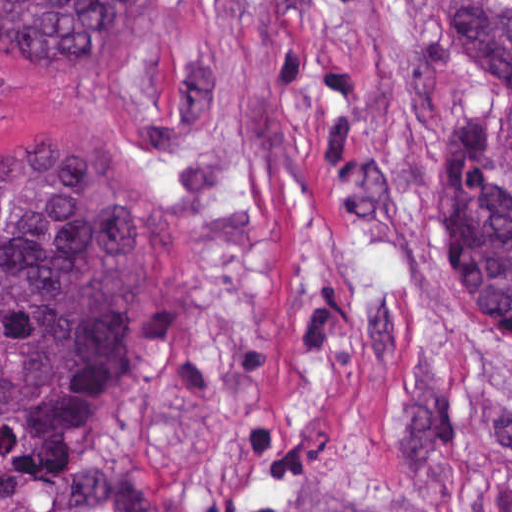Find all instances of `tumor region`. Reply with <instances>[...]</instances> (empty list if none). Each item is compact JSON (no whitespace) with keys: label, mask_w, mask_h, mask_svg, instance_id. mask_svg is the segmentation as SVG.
<instances>
[{"label":"tumor region","mask_w":512,"mask_h":512,"mask_svg":"<svg viewBox=\"0 0 512 512\" xmlns=\"http://www.w3.org/2000/svg\"><path fill=\"white\" fill-rule=\"evenodd\" d=\"M495 94L432 166L415 237L512 353V0H443ZM148 0H0V68L101 64ZM175 316L172 230L134 176L77 136L0 157V493L66 461Z\"/></svg>","instance_id":"obj_1"}]
</instances>
